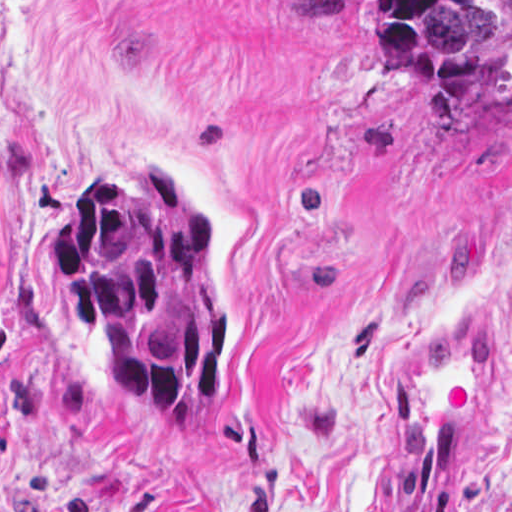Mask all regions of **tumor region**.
I'll return each mask as SVG.
<instances>
[{"mask_svg":"<svg viewBox=\"0 0 512 512\" xmlns=\"http://www.w3.org/2000/svg\"><path fill=\"white\" fill-rule=\"evenodd\" d=\"M269 1L310 33L370 21L447 114L512 96V0ZM45 266L61 317L97 335L110 390L199 425L229 373L230 339L213 238L160 169L92 176L45 240Z\"/></svg>","mask_w":512,"mask_h":512,"instance_id":"obj_1","label":"tumor region"}]
</instances>
